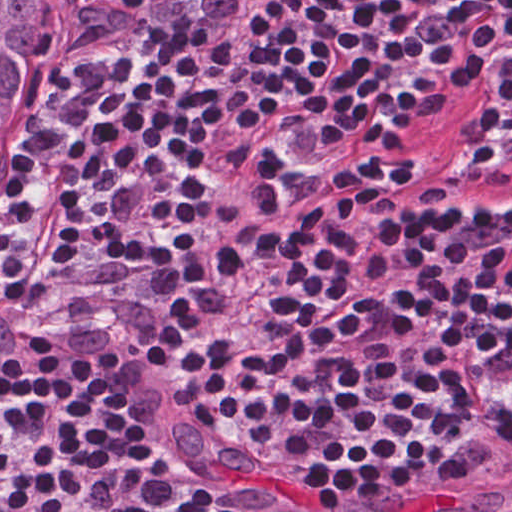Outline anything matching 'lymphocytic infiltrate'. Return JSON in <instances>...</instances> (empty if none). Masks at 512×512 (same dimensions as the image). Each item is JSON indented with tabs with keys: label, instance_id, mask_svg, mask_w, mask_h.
I'll use <instances>...</instances> for the list:
<instances>
[{
	"label": "lymphocytic infiltrate",
	"instance_id": "lymphocytic-infiltrate-1",
	"mask_svg": "<svg viewBox=\"0 0 512 512\" xmlns=\"http://www.w3.org/2000/svg\"><path fill=\"white\" fill-rule=\"evenodd\" d=\"M58 38L0 147V512H283L43 290L329 506L512 484V0H66Z\"/></svg>",
	"mask_w": 512,
	"mask_h": 512
}]
</instances>
